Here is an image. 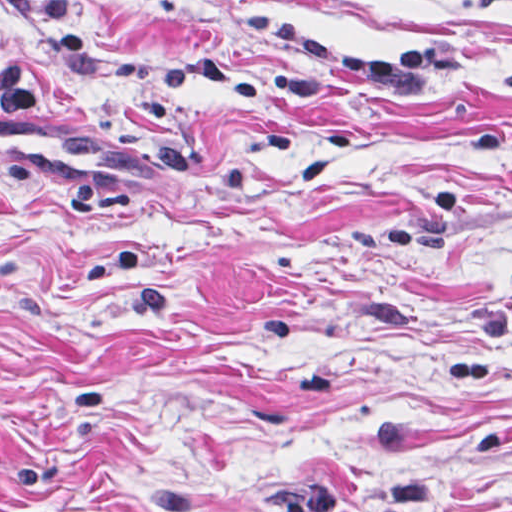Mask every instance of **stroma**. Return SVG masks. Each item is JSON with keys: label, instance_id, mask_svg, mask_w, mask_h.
Wrapping results in <instances>:
<instances>
[{"label": "stroma", "instance_id": "1", "mask_svg": "<svg viewBox=\"0 0 512 512\" xmlns=\"http://www.w3.org/2000/svg\"><path fill=\"white\" fill-rule=\"evenodd\" d=\"M0 512H512V1L0 0Z\"/></svg>", "mask_w": 512, "mask_h": 512}]
</instances>
